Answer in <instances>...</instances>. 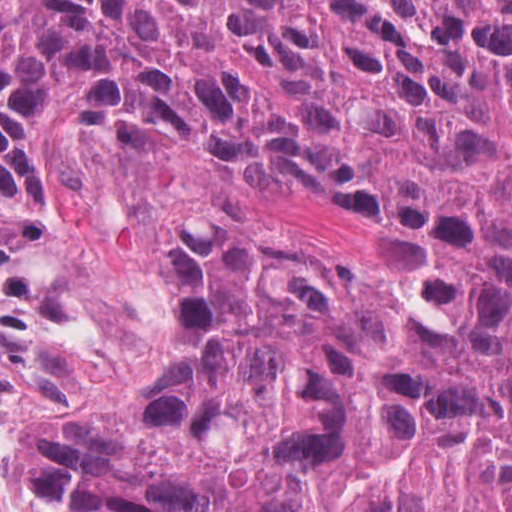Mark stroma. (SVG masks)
<instances>
[{"instance_id":"1","label":"stroma","mask_w":512,"mask_h":512,"mask_svg":"<svg viewBox=\"0 0 512 512\" xmlns=\"http://www.w3.org/2000/svg\"><path fill=\"white\" fill-rule=\"evenodd\" d=\"M52 147L61 194L48 225L0 205V435L37 408L77 418L167 383L179 353L160 326L170 215L223 211L386 264L375 219L317 177L153 149L104 119L55 125Z\"/></svg>"}]
</instances>
